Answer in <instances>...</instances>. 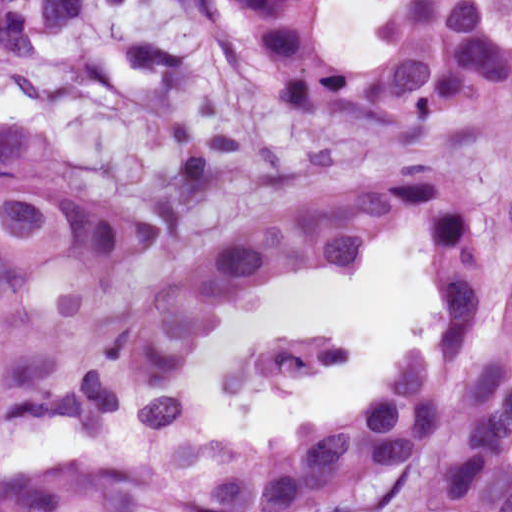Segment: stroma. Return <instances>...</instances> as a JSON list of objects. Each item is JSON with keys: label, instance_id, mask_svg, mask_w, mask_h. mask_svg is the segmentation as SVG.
<instances>
[{"label": "stroma", "instance_id": "35a3bbf8", "mask_svg": "<svg viewBox=\"0 0 512 512\" xmlns=\"http://www.w3.org/2000/svg\"><path fill=\"white\" fill-rule=\"evenodd\" d=\"M7 127L44 143L77 202L175 220L140 279L104 306L0 321V356L35 341L104 339L207 247L308 200L418 169L476 200L495 255L477 351L501 332L512 284V103L436 133L319 124L250 69L220 0H101L77 33L0 62ZM427 282L430 291L428 264ZM172 405L171 421L142 425L140 449L121 466L0 476V512H316L345 499L308 433L235 446Z\"/></svg>", "mask_w": 512, "mask_h": 512}]
</instances>
